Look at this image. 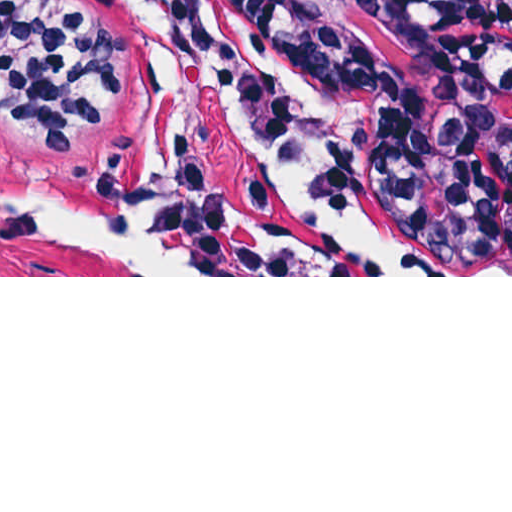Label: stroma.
Returning <instances> with one entry per match:
<instances>
[{
  "instance_id": "stroma-1",
  "label": "stroma",
  "mask_w": 512,
  "mask_h": 512,
  "mask_svg": "<svg viewBox=\"0 0 512 512\" xmlns=\"http://www.w3.org/2000/svg\"><path fill=\"white\" fill-rule=\"evenodd\" d=\"M120 50L69 157L0 123V170L99 197L159 78L124 0H69ZM182 72L155 221L202 276H148L0 209V277H512V63L408 0H176Z\"/></svg>"
}]
</instances>
